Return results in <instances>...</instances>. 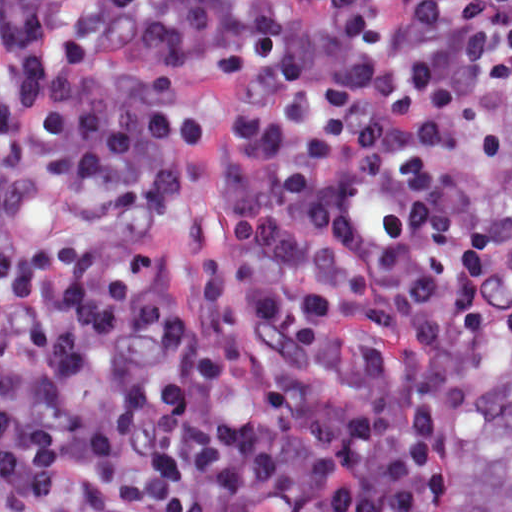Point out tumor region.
I'll use <instances>...</instances> for the list:
<instances>
[{
  "label": "tumor region",
  "mask_w": 512,
  "mask_h": 512,
  "mask_svg": "<svg viewBox=\"0 0 512 512\" xmlns=\"http://www.w3.org/2000/svg\"><path fill=\"white\" fill-rule=\"evenodd\" d=\"M481 242V331L435 512H512V93Z\"/></svg>",
  "instance_id": "1"
}]
</instances>
